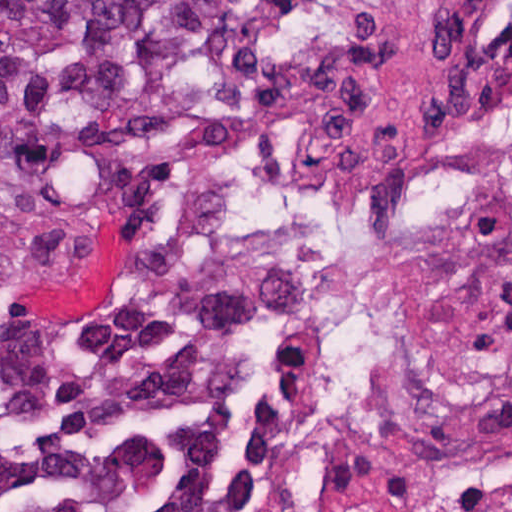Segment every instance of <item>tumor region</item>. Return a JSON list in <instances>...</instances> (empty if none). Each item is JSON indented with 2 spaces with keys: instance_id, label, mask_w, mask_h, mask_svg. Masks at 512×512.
Here are the masks:
<instances>
[{
  "instance_id": "obj_1",
  "label": "tumor region",
  "mask_w": 512,
  "mask_h": 512,
  "mask_svg": "<svg viewBox=\"0 0 512 512\" xmlns=\"http://www.w3.org/2000/svg\"><path fill=\"white\" fill-rule=\"evenodd\" d=\"M258 55L246 0H0V219L161 172ZM170 221L140 228L96 313L1 335L27 512H277L242 440L265 347Z\"/></svg>"
}]
</instances>
